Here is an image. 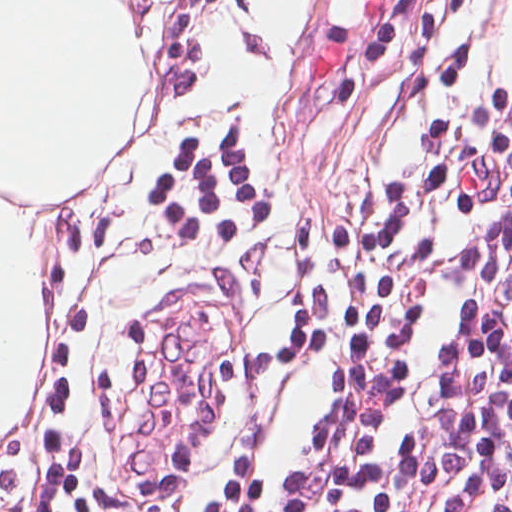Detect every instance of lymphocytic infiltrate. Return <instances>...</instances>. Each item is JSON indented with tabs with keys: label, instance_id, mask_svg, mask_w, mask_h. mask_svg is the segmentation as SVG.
<instances>
[{
	"label": "lymphocytic infiltrate",
	"instance_id": "f902f5d3",
	"mask_svg": "<svg viewBox=\"0 0 512 512\" xmlns=\"http://www.w3.org/2000/svg\"><path fill=\"white\" fill-rule=\"evenodd\" d=\"M233 512H512V135L406 169L363 226L289 451Z\"/></svg>",
	"mask_w": 512,
	"mask_h": 512
}]
</instances>
